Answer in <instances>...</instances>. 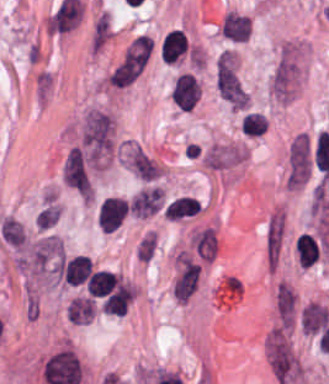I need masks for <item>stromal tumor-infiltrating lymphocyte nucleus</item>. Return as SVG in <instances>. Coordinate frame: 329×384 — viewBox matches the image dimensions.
<instances>
[{"instance_id": "stromal-tumor-infiltrating-lymphocyte-nucleus-2", "label": "stromal tumor-infiltrating lymphocyte nucleus", "mask_w": 329, "mask_h": 384, "mask_svg": "<svg viewBox=\"0 0 329 384\" xmlns=\"http://www.w3.org/2000/svg\"><path fill=\"white\" fill-rule=\"evenodd\" d=\"M199 96V82L190 71H182L175 76L170 89V97L180 108L192 110Z\"/></svg>"}, {"instance_id": "stromal-tumor-infiltrating-lymphocyte-nucleus-8", "label": "stromal tumor-infiltrating lymphocyte nucleus", "mask_w": 329, "mask_h": 384, "mask_svg": "<svg viewBox=\"0 0 329 384\" xmlns=\"http://www.w3.org/2000/svg\"><path fill=\"white\" fill-rule=\"evenodd\" d=\"M300 265L312 266L319 258L318 248L307 234H300L295 242Z\"/></svg>"}, {"instance_id": "stromal-tumor-infiltrating-lymphocyte-nucleus-6", "label": "stromal tumor-infiltrating lymphocyte nucleus", "mask_w": 329, "mask_h": 384, "mask_svg": "<svg viewBox=\"0 0 329 384\" xmlns=\"http://www.w3.org/2000/svg\"><path fill=\"white\" fill-rule=\"evenodd\" d=\"M201 204L195 197L179 196L175 197L166 207L164 217L180 219L196 214Z\"/></svg>"}, {"instance_id": "stromal-tumor-infiltrating-lymphocyte-nucleus-3", "label": "stromal tumor-infiltrating lymphocyte nucleus", "mask_w": 329, "mask_h": 384, "mask_svg": "<svg viewBox=\"0 0 329 384\" xmlns=\"http://www.w3.org/2000/svg\"><path fill=\"white\" fill-rule=\"evenodd\" d=\"M92 272L91 259L84 254H76L63 262L60 273L65 281L84 282Z\"/></svg>"}, {"instance_id": "stromal-tumor-infiltrating-lymphocyte-nucleus-4", "label": "stromal tumor-infiltrating lymphocyte nucleus", "mask_w": 329, "mask_h": 384, "mask_svg": "<svg viewBox=\"0 0 329 384\" xmlns=\"http://www.w3.org/2000/svg\"><path fill=\"white\" fill-rule=\"evenodd\" d=\"M130 298L129 285L117 283L105 296L101 307L106 313L123 314Z\"/></svg>"}, {"instance_id": "stromal-tumor-infiltrating-lymphocyte-nucleus-7", "label": "stromal tumor-infiltrating lymphocyte nucleus", "mask_w": 329, "mask_h": 384, "mask_svg": "<svg viewBox=\"0 0 329 384\" xmlns=\"http://www.w3.org/2000/svg\"><path fill=\"white\" fill-rule=\"evenodd\" d=\"M94 311V299L89 296H75L67 308V315L74 323H87Z\"/></svg>"}, {"instance_id": "stromal-tumor-infiltrating-lymphocyte-nucleus-5", "label": "stromal tumor-infiltrating lymphocyte nucleus", "mask_w": 329, "mask_h": 384, "mask_svg": "<svg viewBox=\"0 0 329 384\" xmlns=\"http://www.w3.org/2000/svg\"><path fill=\"white\" fill-rule=\"evenodd\" d=\"M115 282L116 276L114 272L106 269H99L91 273L85 287L89 293L96 297H103L114 289Z\"/></svg>"}, {"instance_id": "stromal-tumor-infiltrating-lymphocyte-nucleus-1", "label": "stromal tumor-infiltrating lymphocyte nucleus", "mask_w": 329, "mask_h": 384, "mask_svg": "<svg viewBox=\"0 0 329 384\" xmlns=\"http://www.w3.org/2000/svg\"><path fill=\"white\" fill-rule=\"evenodd\" d=\"M190 54V42L186 34L177 28H170L160 44V61L166 65H174Z\"/></svg>"}, {"instance_id": "stromal-tumor-infiltrating-lymphocyte-nucleus-9", "label": "stromal tumor-infiltrating lymphocyte nucleus", "mask_w": 329, "mask_h": 384, "mask_svg": "<svg viewBox=\"0 0 329 384\" xmlns=\"http://www.w3.org/2000/svg\"><path fill=\"white\" fill-rule=\"evenodd\" d=\"M266 118L259 111H245L240 118L239 129L245 136H259L265 129Z\"/></svg>"}]
</instances>
